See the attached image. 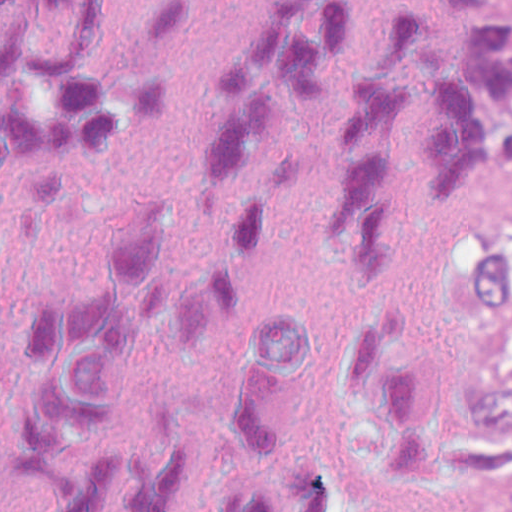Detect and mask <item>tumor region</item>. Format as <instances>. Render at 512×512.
I'll list each match as a JSON object with an SVG mask.
<instances>
[{"label": "tumor region", "instance_id": "obj_1", "mask_svg": "<svg viewBox=\"0 0 512 512\" xmlns=\"http://www.w3.org/2000/svg\"><path fill=\"white\" fill-rule=\"evenodd\" d=\"M512 151V0L484 84L472 188ZM435 424L464 512H512V216L466 221Z\"/></svg>", "mask_w": 512, "mask_h": 512}]
</instances>
